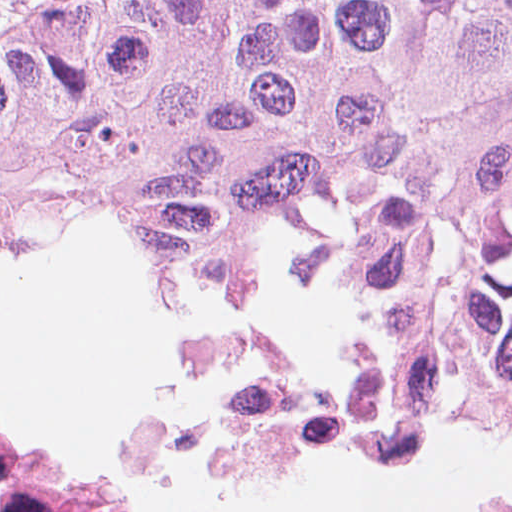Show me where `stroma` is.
<instances>
[{
  "label": "stroma",
  "mask_w": 512,
  "mask_h": 512,
  "mask_svg": "<svg viewBox=\"0 0 512 512\" xmlns=\"http://www.w3.org/2000/svg\"><path fill=\"white\" fill-rule=\"evenodd\" d=\"M64 1L70 0H0V32Z\"/></svg>",
  "instance_id": "stroma-1"
}]
</instances>
